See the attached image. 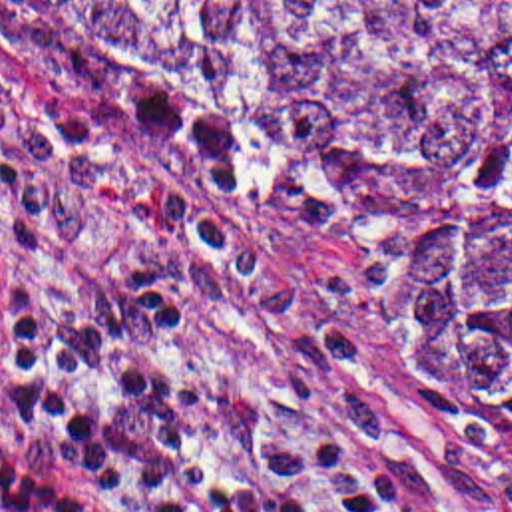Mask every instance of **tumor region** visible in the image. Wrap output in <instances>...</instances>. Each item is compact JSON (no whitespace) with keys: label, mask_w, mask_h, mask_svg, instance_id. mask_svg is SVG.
<instances>
[{"label":"tumor region","mask_w":512,"mask_h":512,"mask_svg":"<svg viewBox=\"0 0 512 512\" xmlns=\"http://www.w3.org/2000/svg\"><path fill=\"white\" fill-rule=\"evenodd\" d=\"M87 147L306 253L512 466V0H0Z\"/></svg>","instance_id":"e687c5a6"}]
</instances>
